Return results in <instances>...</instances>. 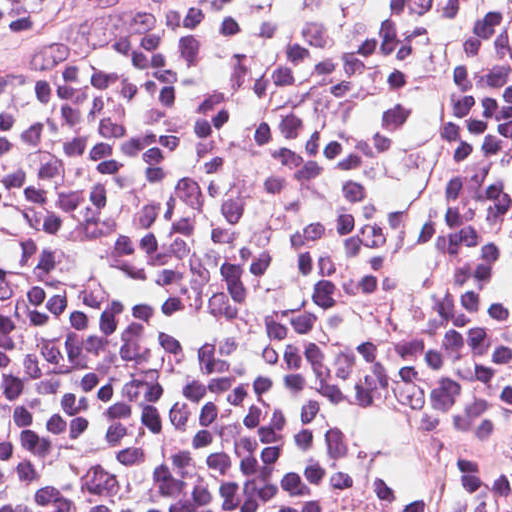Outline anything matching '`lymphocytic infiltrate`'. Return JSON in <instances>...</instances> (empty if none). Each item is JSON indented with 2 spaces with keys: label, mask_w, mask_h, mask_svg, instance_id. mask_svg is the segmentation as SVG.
<instances>
[{
  "label": "lymphocytic infiltrate",
  "mask_w": 512,
  "mask_h": 512,
  "mask_svg": "<svg viewBox=\"0 0 512 512\" xmlns=\"http://www.w3.org/2000/svg\"><path fill=\"white\" fill-rule=\"evenodd\" d=\"M0 512H512V0H0Z\"/></svg>",
  "instance_id": "f902f5d3"
}]
</instances>
